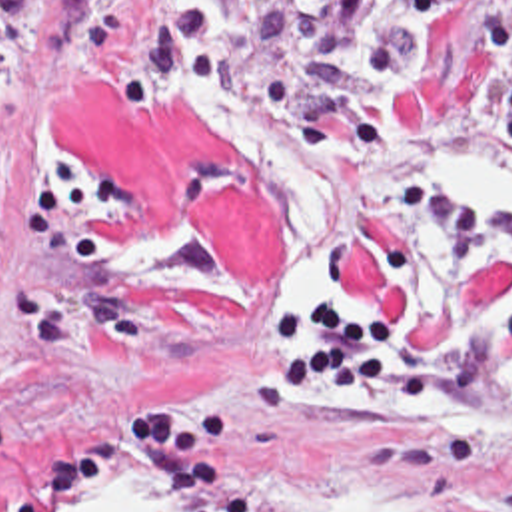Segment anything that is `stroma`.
<instances>
[{"label": "stroma", "mask_w": 512, "mask_h": 512, "mask_svg": "<svg viewBox=\"0 0 512 512\" xmlns=\"http://www.w3.org/2000/svg\"><path fill=\"white\" fill-rule=\"evenodd\" d=\"M329 0H39L0 75V512L149 479L187 512H512V213H409L295 311L265 199L181 131L213 79L281 119ZM395 145H512V0L433 19Z\"/></svg>", "instance_id": "1"}]
</instances>
